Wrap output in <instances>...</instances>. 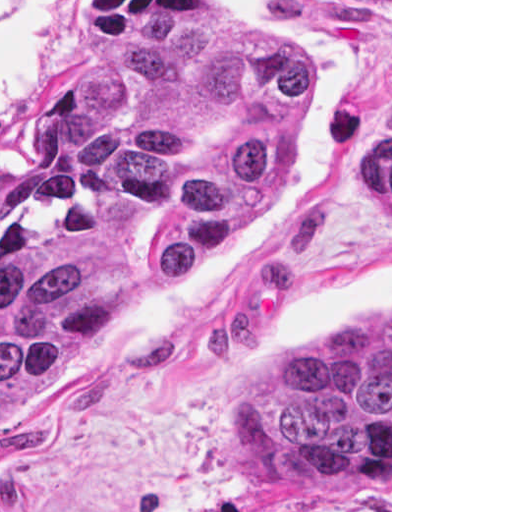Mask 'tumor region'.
Listing matches in <instances>:
<instances>
[{
    "label": "tumor region",
    "instance_id": "e687c5a6",
    "mask_svg": "<svg viewBox=\"0 0 512 512\" xmlns=\"http://www.w3.org/2000/svg\"><path fill=\"white\" fill-rule=\"evenodd\" d=\"M300 104L296 52L260 31L160 34L87 57L42 136L36 181L0 212V405L216 247ZM356 178L390 206V134L356 145ZM246 454L273 486L389 482L390 314L322 324L272 363L246 399Z\"/></svg>",
    "mask_w": 512,
    "mask_h": 512
}]
</instances>
